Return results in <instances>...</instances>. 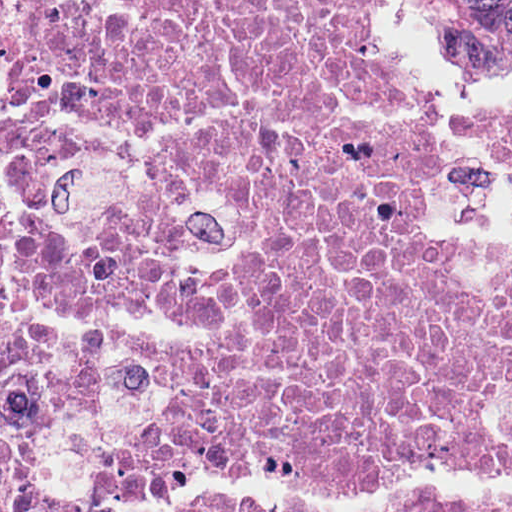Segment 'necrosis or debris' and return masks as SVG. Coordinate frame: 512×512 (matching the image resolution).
Returning <instances> with one entry per match:
<instances>
[{
	"label": "necrosis or debris",
	"instance_id": "necrosis-or-debris-1",
	"mask_svg": "<svg viewBox=\"0 0 512 512\" xmlns=\"http://www.w3.org/2000/svg\"><path fill=\"white\" fill-rule=\"evenodd\" d=\"M8 3L0 512H512V250L435 241L377 0Z\"/></svg>",
	"mask_w": 512,
	"mask_h": 512
}]
</instances>
